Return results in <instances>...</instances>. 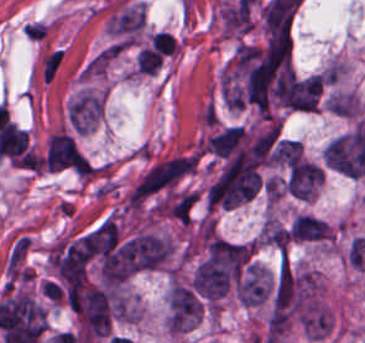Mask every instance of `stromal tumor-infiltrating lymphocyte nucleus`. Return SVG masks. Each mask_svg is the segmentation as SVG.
Wrapping results in <instances>:
<instances>
[{
	"label": "stromal tumor-infiltrating lymphocyte nucleus",
	"instance_id": "1",
	"mask_svg": "<svg viewBox=\"0 0 365 343\" xmlns=\"http://www.w3.org/2000/svg\"><path fill=\"white\" fill-rule=\"evenodd\" d=\"M150 44L160 55L171 56L177 51L174 39L166 30H159L151 35Z\"/></svg>",
	"mask_w": 365,
	"mask_h": 343
}]
</instances>
